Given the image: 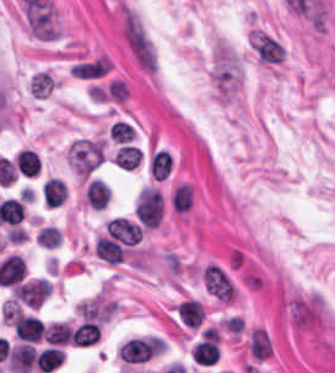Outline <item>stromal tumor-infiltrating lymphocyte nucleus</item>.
Masks as SVG:
<instances>
[{
    "label": "stromal tumor-infiltrating lymphocyte nucleus",
    "instance_id": "6",
    "mask_svg": "<svg viewBox=\"0 0 335 373\" xmlns=\"http://www.w3.org/2000/svg\"><path fill=\"white\" fill-rule=\"evenodd\" d=\"M64 355L60 346L48 345L38 351L34 363L42 372H50L59 365Z\"/></svg>",
    "mask_w": 335,
    "mask_h": 373
},
{
    "label": "stromal tumor-infiltrating lymphocyte nucleus",
    "instance_id": "3",
    "mask_svg": "<svg viewBox=\"0 0 335 373\" xmlns=\"http://www.w3.org/2000/svg\"><path fill=\"white\" fill-rule=\"evenodd\" d=\"M16 336L20 340L38 341L41 336L39 318L35 314L18 313L12 320Z\"/></svg>",
    "mask_w": 335,
    "mask_h": 373
},
{
    "label": "stromal tumor-infiltrating lymphocyte nucleus",
    "instance_id": "13",
    "mask_svg": "<svg viewBox=\"0 0 335 373\" xmlns=\"http://www.w3.org/2000/svg\"><path fill=\"white\" fill-rule=\"evenodd\" d=\"M36 242L47 248H54L61 242V232L50 224L40 226L34 236Z\"/></svg>",
    "mask_w": 335,
    "mask_h": 373
},
{
    "label": "stromal tumor-infiltrating lymphocyte nucleus",
    "instance_id": "10",
    "mask_svg": "<svg viewBox=\"0 0 335 373\" xmlns=\"http://www.w3.org/2000/svg\"><path fill=\"white\" fill-rule=\"evenodd\" d=\"M141 154L136 145L124 143L113 153L112 159L116 165L123 168H131L140 161Z\"/></svg>",
    "mask_w": 335,
    "mask_h": 373
},
{
    "label": "stromal tumor-infiltrating lymphocyte nucleus",
    "instance_id": "9",
    "mask_svg": "<svg viewBox=\"0 0 335 373\" xmlns=\"http://www.w3.org/2000/svg\"><path fill=\"white\" fill-rule=\"evenodd\" d=\"M15 163L22 175L34 176L39 173L40 159L38 152L24 148L18 152Z\"/></svg>",
    "mask_w": 335,
    "mask_h": 373
},
{
    "label": "stromal tumor-infiltrating lymphocyte nucleus",
    "instance_id": "2",
    "mask_svg": "<svg viewBox=\"0 0 335 373\" xmlns=\"http://www.w3.org/2000/svg\"><path fill=\"white\" fill-rule=\"evenodd\" d=\"M104 228L105 232L123 245H132L141 234V228L121 216H114Z\"/></svg>",
    "mask_w": 335,
    "mask_h": 373
},
{
    "label": "stromal tumor-infiltrating lymphocyte nucleus",
    "instance_id": "8",
    "mask_svg": "<svg viewBox=\"0 0 335 373\" xmlns=\"http://www.w3.org/2000/svg\"><path fill=\"white\" fill-rule=\"evenodd\" d=\"M44 201L47 206L61 204L65 199V182L56 176H49L42 184Z\"/></svg>",
    "mask_w": 335,
    "mask_h": 373
},
{
    "label": "stromal tumor-infiltrating lymphocyte nucleus",
    "instance_id": "7",
    "mask_svg": "<svg viewBox=\"0 0 335 373\" xmlns=\"http://www.w3.org/2000/svg\"><path fill=\"white\" fill-rule=\"evenodd\" d=\"M99 327L97 322L81 321L71 331V342L76 345H89L98 340Z\"/></svg>",
    "mask_w": 335,
    "mask_h": 373
},
{
    "label": "stromal tumor-infiltrating lymphocyte nucleus",
    "instance_id": "1",
    "mask_svg": "<svg viewBox=\"0 0 335 373\" xmlns=\"http://www.w3.org/2000/svg\"><path fill=\"white\" fill-rule=\"evenodd\" d=\"M163 204L158 190L143 186L137 195L133 211L144 228H153L162 216Z\"/></svg>",
    "mask_w": 335,
    "mask_h": 373
},
{
    "label": "stromal tumor-infiltrating lymphocyte nucleus",
    "instance_id": "12",
    "mask_svg": "<svg viewBox=\"0 0 335 373\" xmlns=\"http://www.w3.org/2000/svg\"><path fill=\"white\" fill-rule=\"evenodd\" d=\"M169 202L174 210L186 211L191 203V189L186 182L173 186L169 194Z\"/></svg>",
    "mask_w": 335,
    "mask_h": 373
},
{
    "label": "stromal tumor-infiltrating lymphocyte nucleus",
    "instance_id": "5",
    "mask_svg": "<svg viewBox=\"0 0 335 373\" xmlns=\"http://www.w3.org/2000/svg\"><path fill=\"white\" fill-rule=\"evenodd\" d=\"M110 199V187L99 179L88 182L85 191V200L93 210H102Z\"/></svg>",
    "mask_w": 335,
    "mask_h": 373
},
{
    "label": "stromal tumor-infiltrating lymphocyte nucleus",
    "instance_id": "11",
    "mask_svg": "<svg viewBox=\"0 0 335 373\" xmlns=\"http://www.w3.org/2000/svg\"><path fill=\"white\" fill-rule=\"evenodd\" d=\"M71 331L65 322H51L44 330V340L50 345H64L70 340Z\"/></svg>",
    "mask_w": 335,
    "mask_h": 373
},
{
    "label": "stromal tumor-infiltrating lymphocyte nucleus",
    "instance_id": "4",
    "mask_svg": "<svg viewBox=\"0 0 335 373\" xmlns=\"http://www.w3.org/2000/svg\"><path fill=\"white\" fill-rule=\"evenodd\" d=\"M93 249L107 264H115L124 255L119 241L110 236H97Z\"/></svg>",
    "mask_w": 335,
    "mask_h": 373
},
{
    "label": "stromal tumor-infiltrating lymphocyte nucleus",
    "instance_id": "14",
    "mask_svg": "<svg viewBox=\"0 0 335 373\" xmlns=\"http://www.w3.org/2000/svg\"><path fill=\"white\" fill-rule=\"evenodd\" d=\"M108 134L114 141L122 143L132 137L134 128L129 123L117 119L110 125Z\"/></svg>",
    "mask_w": 335,
    "mask_h": 373
}]
</instances>
